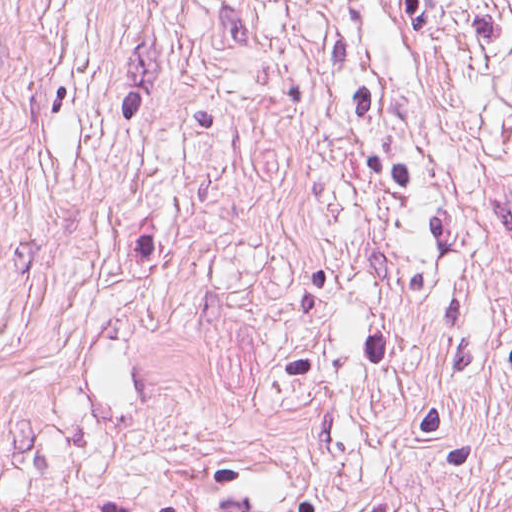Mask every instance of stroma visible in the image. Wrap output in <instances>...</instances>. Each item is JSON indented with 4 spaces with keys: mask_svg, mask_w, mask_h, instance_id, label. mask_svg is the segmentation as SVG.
<instances>
[{
    "mask_svg": "<svg viewBox=\"0 0 512 512\" xmlns=\"http://www.w3.org/2000/svg\"><path fill=\"white\" fill-rule=\"evenodd\" d=\"M0 512H512V0H0Z\"/></svg>",
    "mask_w": 512,
    "mask_h": 512,
    "instance_id": "obj_1",
    "label": "stroma"
}]
</instances>
